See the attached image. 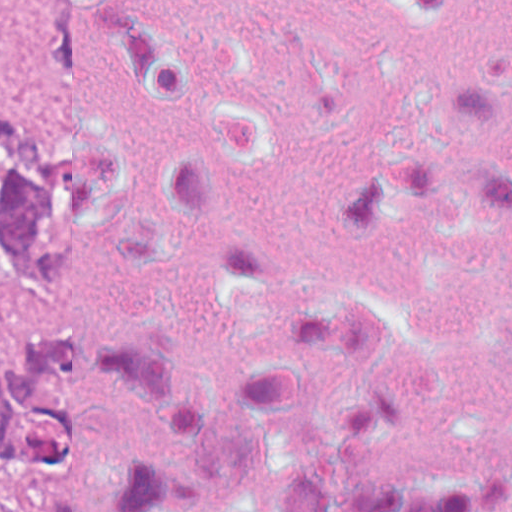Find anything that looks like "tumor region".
I'll use <instances>...</instances> for the list:
<instances>
[{
	"label": "tumor region",
	"mask_w": 512,
	"mask_h": 512,
	"mask_svg": "<svg viewBox=\"0 0 512 512\" xmlns=\"http://www.w3.org/2000/svg\"><path fill=\"white\" fill-rule=\"evenodd\" d=\"M22 50L23 29L0 26V64ZM55 153L56 119L0 108V512H13L18 468H45V245Z\"/></svg>",
	"instance_id": "tumor-region-1"
}]
</instances>
